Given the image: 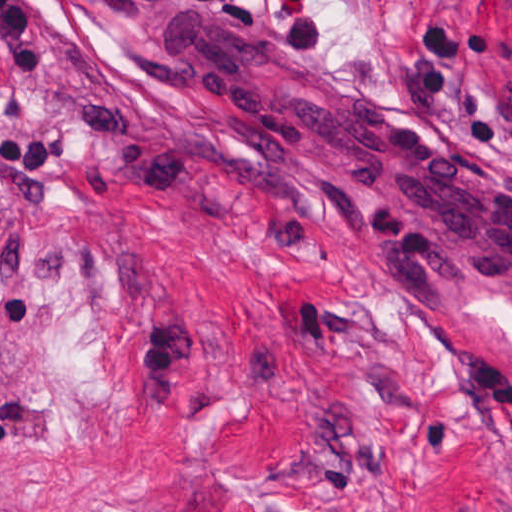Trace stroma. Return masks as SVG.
<instances>
[{
	"label": "stroma",
	"instance_id": "35a3bbf8",
	"mask_svg": "<svg viewBox=\"0 0 512 512\" xmlns=\"http://www.w3.org/2000/svg\"><path fill=\"white\" fill-rule=\"evenodd\" d=\"M512 175V0H235ZM215 113L99 0H0V512H512V307L432 316L330 211L206 172Z\"/></svg>",
	"mask_w": 512,
	"mask_h": 512
}]
</instances>
